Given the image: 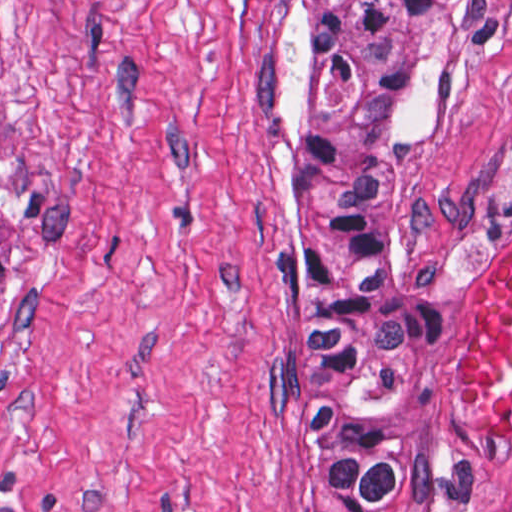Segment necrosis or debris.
Returning a JSON list of instances; mask_svg holds the SVG:
<instances>
[{
    "instance_id": "1",
    "label": "necrosis or debris",
    "mask_w": 512,
    "mask_h": 512,
    "mask_svg": "<svg viewBox=\"0 0 512 512\" xmlns=\"http://www.w3.org/2000/svg\"><path fill=\"white\" fill-rule=\"evenodd\" d=\"M440 512H512V462Z\"/></svg>"
}]
</instances>
